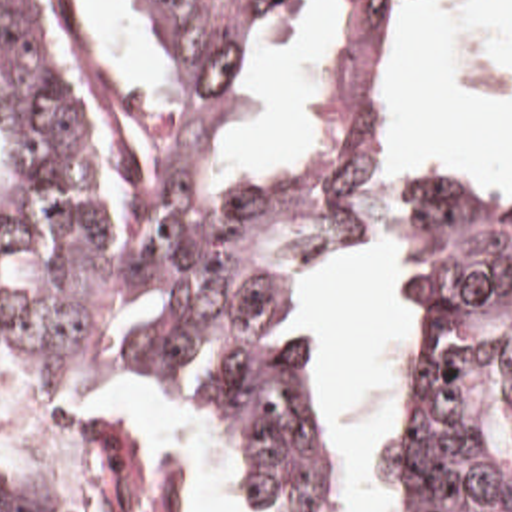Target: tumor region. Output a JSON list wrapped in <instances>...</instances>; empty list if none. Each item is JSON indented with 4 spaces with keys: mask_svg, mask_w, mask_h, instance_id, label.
Segmentation results:
<instances>
[{
    "mask_svg": "<svg viewBox=\"0 0 512 512\" xmlns=\"http://www.w3.org/2000/svg\"><path fill=\"white\" fill-rule=\"evenodd\" d=\"M193 88L217 94L291 0H149ZM395 0H349L327 64V152L305 178L213 200L181 114L141 126L167 190L131 262L105 238V176L27 8L0 0V364L37 432L0 512H121V386L213 376L251 512H343L347 471L295 316L313 258L359 228V102ZM403 232L430 354L422 512H512V196L393 164L375 228Z\"/></svg>",
    "mask_w": 512,
    "mask_h": 512,
    "instance_id": "e687c5a6",
    "label": "tumor region"
}]
</instances>
